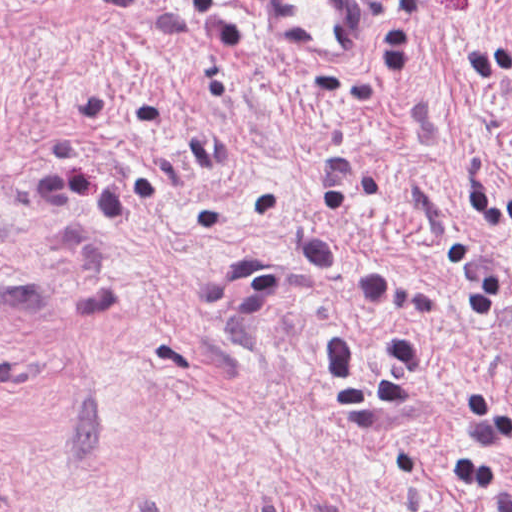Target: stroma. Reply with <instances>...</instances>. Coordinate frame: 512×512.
I'll list each match as a JSON object with an SVG mask.
<instances>
[{
	"label": "stroma",
	"instance_id": "stroma-1",
	"mask_svg": "<svg viewBox=\"0 0 512 512\" xmlns=\"http://www.w3.org/2000/svg\"><path fill=\"white\" fill-rule=\"evenodd\" d=\"M313 60L258 0H0V512H492L512 436V0H358ZM344 326L387 414H341ZM512 480V438L500 448Z\"/></svg>",
	"mask_w": 512,
	"mask_h": 512
}]
</instances>
